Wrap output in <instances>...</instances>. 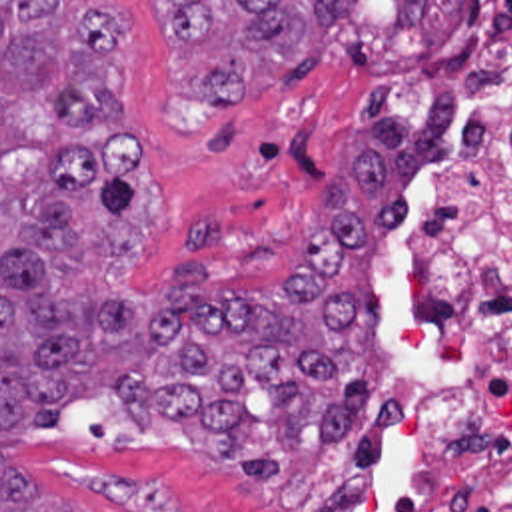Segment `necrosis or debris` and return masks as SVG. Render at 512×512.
Instances as JSON below:
<instances>
[{"mask_svg":"<svg viewBox=\"0 0 512 512\" xmlns=\"http://www.w3.org/2000/svg\"><path fill=\"white\" fill-rule=\"evenodd\" d=\"M286 511L512 512V0H467L404 162L394 340Z\"/></svg>","mask_w":512,"mask_h":512,"instance_id":"obj_1","label":"necrosis or debris"}]
</instances>
